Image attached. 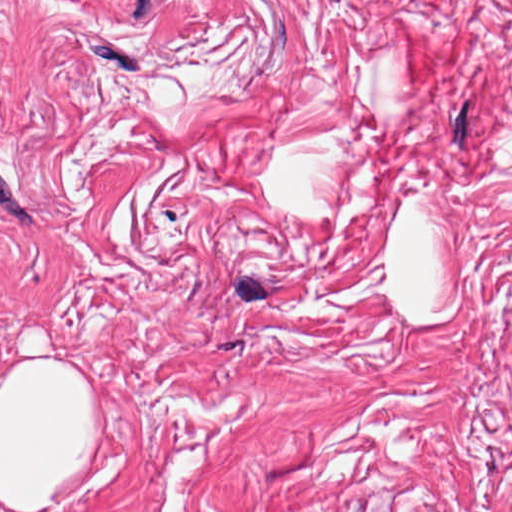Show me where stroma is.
Returning a JSON list of instances; mask_svg holds the SVG:
<instances>
[{
    "label": "stroma",
    "mask_w": 512,
    "mask_h": 512,
    "mask_svg": "<svg viewBox=\"0 0 512 512\" xmlns=\"http://www.w3.org/2000/svg\"><path fill=\"white\" fill-rule=\"evenodd\" d=\"M19 356L102 390L63 512H512V0H0Z\"/></svg>",
    "instance_id": "stroma-1"
}]
</instances>
